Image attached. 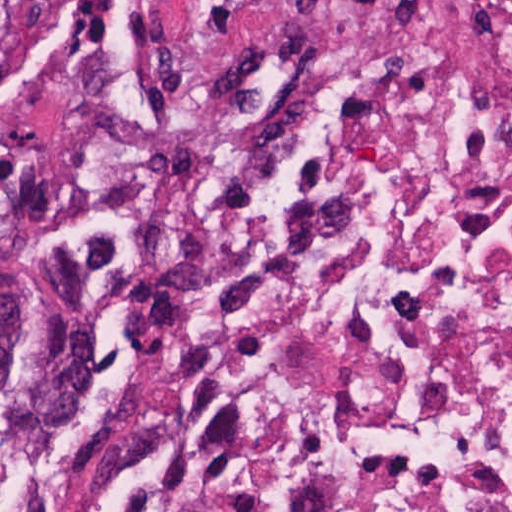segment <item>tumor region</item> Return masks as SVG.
Returning <instances> with one entry per match:
<instances>
[{
    "mask_svg": "<svg viewBox=\"0 0 512 512\" xmlns=\"http://www.w3.org/2000/svg\"><path fill=\"white\" fill-rule=\"evenodd\" d=\"M25 0H0V89L32 71ZM25 371V304L0 244V382Z\"/></svg>",
    "mask_w": 512,
    "mask_h": 512,
    "instance_id": "obj_1",
    "label": "tumor region"
}]
</instances>
